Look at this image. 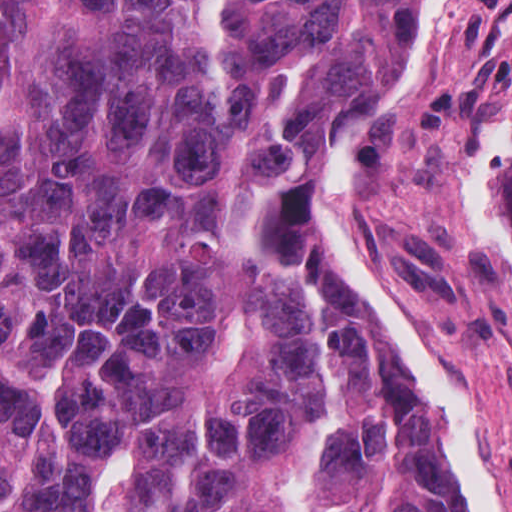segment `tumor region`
Wrapping results in <instances>:
<instances>
[{"instance_id":"1","label":"tumor region","mask_w":512,"mask_h":512,"mask_svg":"<svg viewBox=\"0 0 512 512\" xmlns=\"http://www.w3.org/2000/svg\"><path fill=\"white\" fill-rule=\"evenodd\" d=\"M435 3L0 0V512H465L330 251Z\"/></svg>"}]
</instances>
